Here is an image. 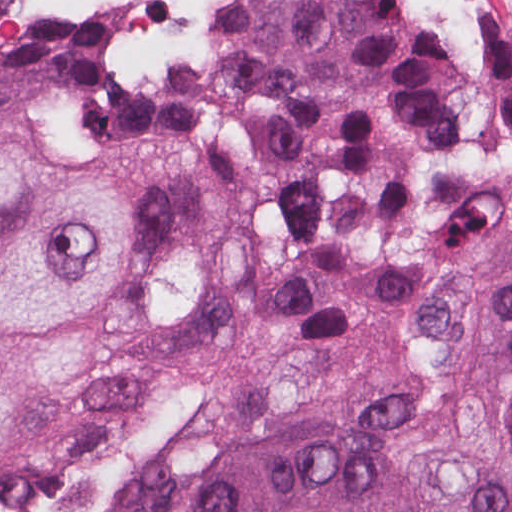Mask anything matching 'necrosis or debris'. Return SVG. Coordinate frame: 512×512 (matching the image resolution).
Instances as JSON below:
<instances>
[{
  "label": "necrosis or debris",
  "instance_id": "obj_1",
  "mask_svg": "<svg viewBox=\"0 0 512 512\" xmlns=\"http://www.w3.org/2000/svg\"><path fill=\"white\" fill-rule=\"evenodd\" d=\"M245 1L111 0L114 43L132 72L165 77L188 70L220 41Z\"/></svg>",
  "mask_w": 512,
  "mask_h": 512
}]
</instances>
